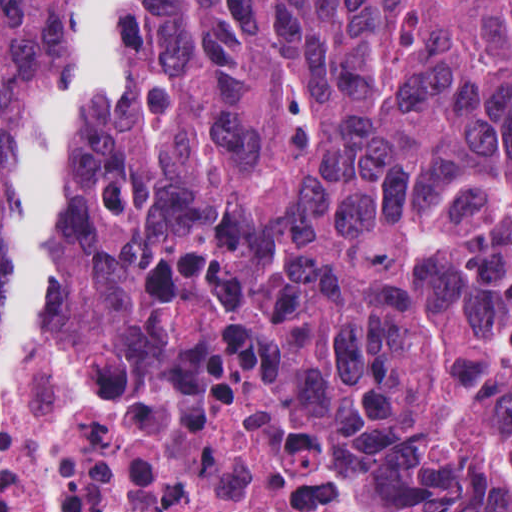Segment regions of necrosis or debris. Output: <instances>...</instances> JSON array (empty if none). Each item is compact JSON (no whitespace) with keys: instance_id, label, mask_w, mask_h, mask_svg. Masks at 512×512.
Wrapping results in <instances>:
<instances>
[{"instance_id":"necrosis-or-debris-1","label":"necrosis or debris","mask_w":512,"mask_h":512,"mask_svg":"<svg viewBox=\"0 0 512 512\" xmlns=\"http://www.w3.org/2000/svg\"><path fill=\"white\" fill-rule=\"evenodd\" d=\"M412 476L339 384L186 367L56 312L7 387L0 512H390Z\"/></svg>"}]
</instances>
